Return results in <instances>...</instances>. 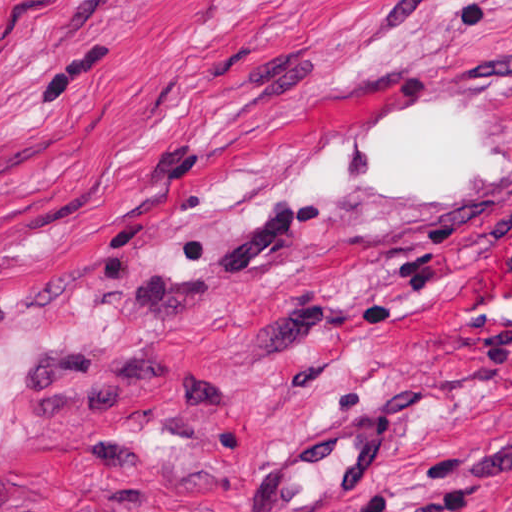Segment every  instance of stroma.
Returning <instances> with one entry per match:
<instances>
[{
	"label": "stroma",
	"mask_w": 512,
	"mask_h": 512,
	"mask_svg": "<svg viewBox=\"0 0 512 512\" xmlns=\"http://www.w3.org/2000/svg\"><path fill=\"white\" fill-rule=\"evenodd\" d=\"M0 512H512V0H0Z\"/></svg>",
	"instance_id": "stroma-1"
}]
</instances>
